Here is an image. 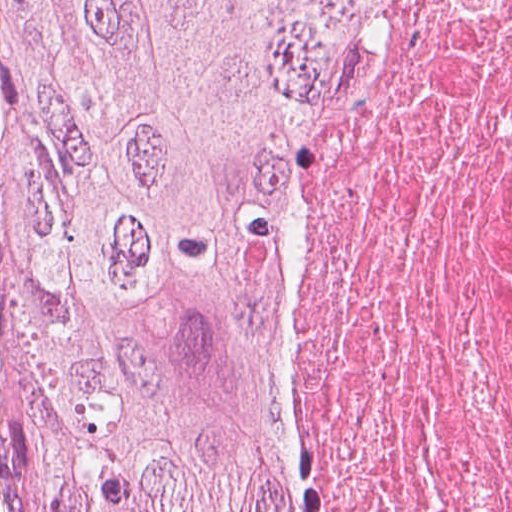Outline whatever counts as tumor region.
I'll return each mask as SVG.
<instances>
[{"mask_svg":"<svg viewBox=\"0 0 512 512\" xmlns=\"http://www.w3.org/2000/svg\"><path fill=\"white\" fill-rule=\"evenodd\" d=\"M383 0H0L23 512H296L252 363L332 66Z\"/></svg>","mask_w":512,"mask_h":512,"instance_id":"tumor-region-1","label":"tumor region"}]
</instances>
